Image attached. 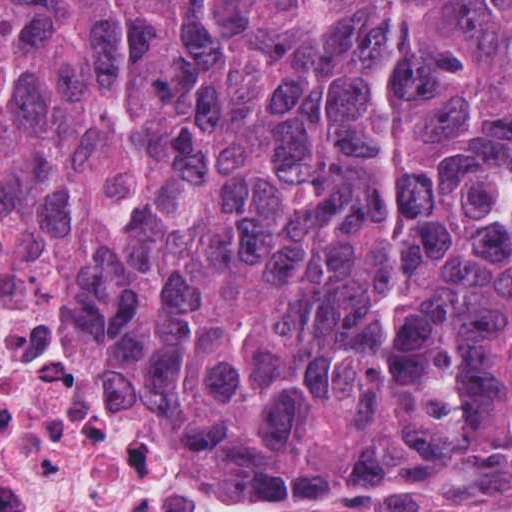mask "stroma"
Segmentation results:
<instances>
[{
    "label": "stroma",
    "mask_w": 512,
    "mask_h": 512,
    "mask_svg": "<svg viewBox=\"0 0 512 512\" xmlns=\"http://www.w3.org/2000/svg\"><path fill=\"white\" fill-rule=\"evenodd\" d=\"M210 484L226 512H512V453L378 496L272 495Z\"/></svg>",
    "instance_id": "35a3bbf8"
}]
</instances>
